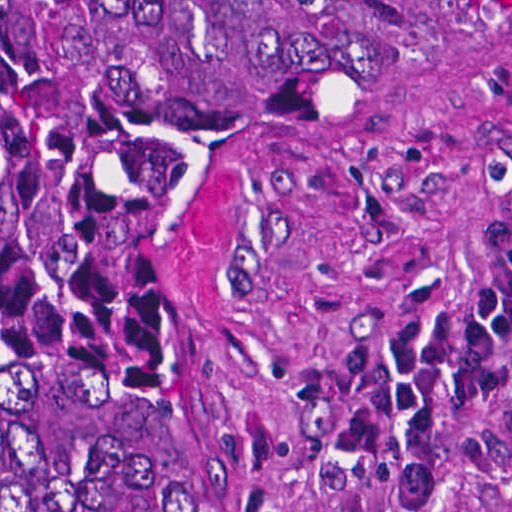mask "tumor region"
Here are the masks:
<instances>
[{"label": "tumor region", "mask_w": 512, "mask_h": 512, "mask_svg": "<svg viewBox=\"0 0 512 512\" xmlns=\"http://www.w3.org/2000/svg\"><path fill=\"white\" fill-rule=\"evenodd\" d=\"M512 0H0V512H188L227 208Z\"/></svg>", "instance_id": "1"}]
</instances>
